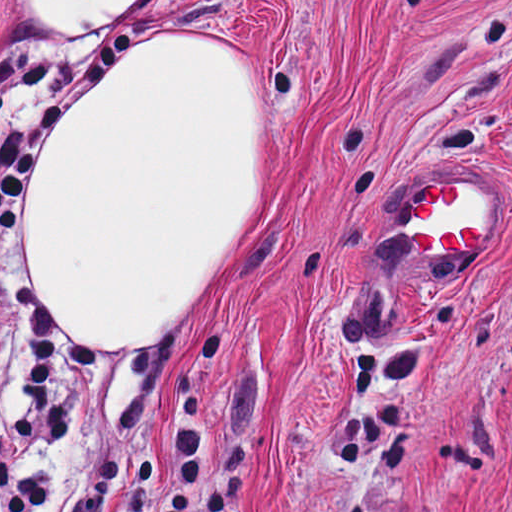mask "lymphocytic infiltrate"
<instances>
[{"instance_id":"obj_1","label":"lymphocytic infiltrate","mask_w":512,"mask_h":512,"mask_svg":"<svg viewBox=\"0 0 512 512\" xmlns=\"http://www.w3.org/2000/svg\"><path fill=\"white\" fill-rule=\"evenodd\" d=\"M138 41L130 20L102 42L84 66L69 72L49 97L31 108V92L48 66L39 55L0 58V233L19 212V178L58 109L94 78L100 67ZM18 310L30 365V408L0 433V512H40L53 462L42 455L52 445L67 453L73 436V377L54 324L18 293ZM179 420L171 450L169 512H189V498L206 467L205 385L181 365L174 378ZM119 463L101 461L92 487L61 512H101L103 494Z\"/></svg>"}]
</instances>
